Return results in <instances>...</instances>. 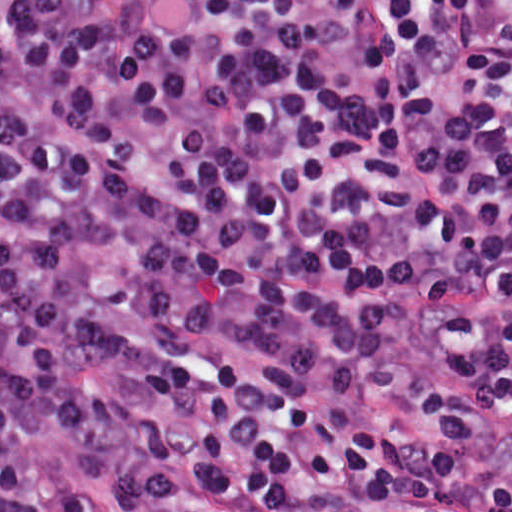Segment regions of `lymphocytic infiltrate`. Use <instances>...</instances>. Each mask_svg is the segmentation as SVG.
I'll use <instances>...</instances> for the list:
<instances>
[{"label":"lymphocytic infiltrate","instance_id":"obj_1","mask_svg":"<svg viewBox=\"0 0 512 512\" xmlns=\"http://www.w3.org/2000/svg\"><path fill=\"white\" fill-rule=\"evenodd\" d=\"M442 305L415 405L512 428V0H0V512L171 474L305 512L512 507L329 388Z\"/></svg>","mask_w":512,"mask_h":512}]
</instances>
